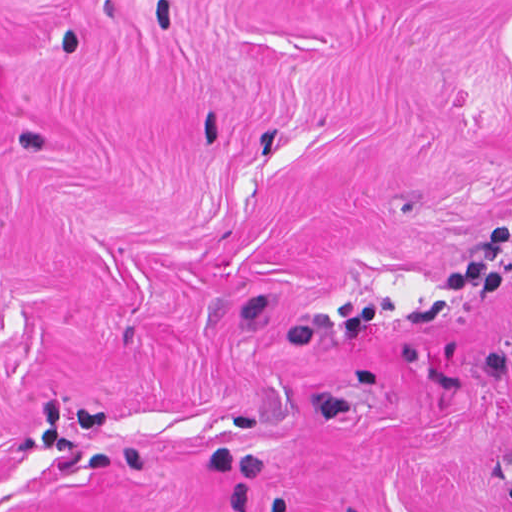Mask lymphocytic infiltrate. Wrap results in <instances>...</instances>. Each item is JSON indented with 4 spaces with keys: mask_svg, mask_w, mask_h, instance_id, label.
<instances>
[{
    "mask_svg": "<svg viewBox=\"0 0 512 512\" xmlns=\"http://www.w3.org/2000/svg\"><path fill=\"white\" fill-rule=\"evenodd\" d=\"M510 247V223H499L484 229L464 260L439 273L436 286L440 291L500 294L504 291Z\"/></svg>",
    "mask_w": 512,
    "mask_h": 512,
    "instance_id": "obj_1",
    "label": "lymphocytic infiltrate"
}]
</instances>
